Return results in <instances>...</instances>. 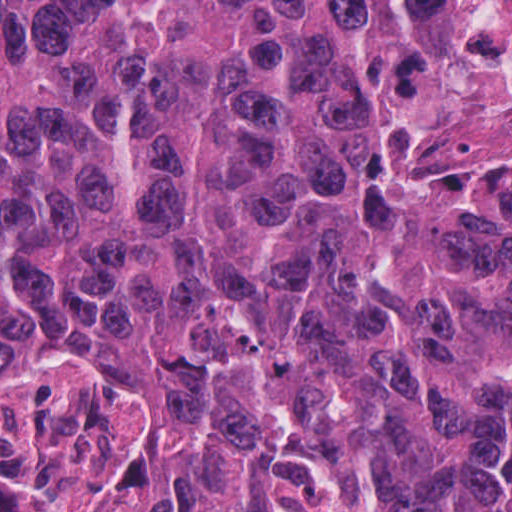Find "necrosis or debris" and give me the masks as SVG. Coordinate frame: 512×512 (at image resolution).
<instances>
[{"label": "necrosis or debris", "mask_w": 512, "mask_h": 512, "mask_svg": "<svg viewBox=\"0 0 512 512\" xmlns=\"http://www.w3.org/2000/svg\"><path fill=\"white\" fill-rule=\"evenodd\" d=\"M356 129L391 175L512 212V0H356Z\"/></svg>", "instance_id": "4bbe7bcc"}]
</instances>
